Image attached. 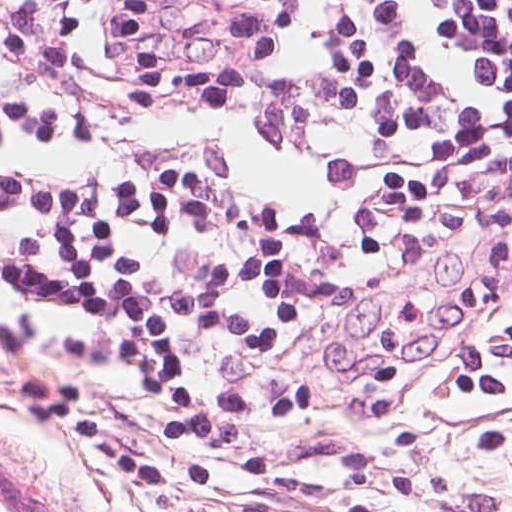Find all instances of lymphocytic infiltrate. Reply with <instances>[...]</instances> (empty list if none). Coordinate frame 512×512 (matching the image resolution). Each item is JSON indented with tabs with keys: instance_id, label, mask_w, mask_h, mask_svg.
Here are the masks:
<instances>
[{
	"instance_id": "1",
	"label": "lymphocytic infiltrate",
	"mask_w": 512,
	"mask_h": 512,
	"mask_svg": "<svg viewBox=\"0 0 512 512\" xmlns=\"http://www.w3.org/2000/svg\"><path fill=\"white\" fill-rule=\"evenodd\" d=\"M512 210V0H0V456L164 490L298 293Z\"/></svg>"
}]
</instances>
